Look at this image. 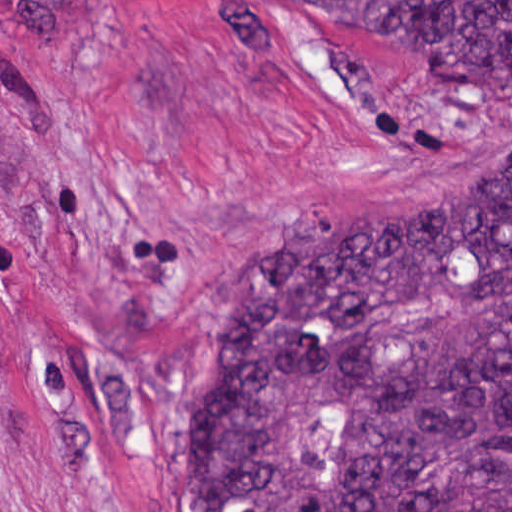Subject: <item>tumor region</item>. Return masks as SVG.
Returning a JSON list of instances; mask_svg holds the SVG:
<instances>
[{
	"label": "tumor region",
	"mask_w": 512,
	"mask_h": 512,
	"mask_svg": "<svg viewBox=\"0 0 512 512\" xmlns=\"http://www.w3.org/2000/svg\"><path fill=\"white\" fill-rule=\"evenodd\" d=\"M87 0H0L15 42ZM340 8L436 81L512 80V0ZM330 214L247 268L209 330L190 512H512V166Z\"/></svg>",
	"instance_id": "obj_1"
}]
</instances>
